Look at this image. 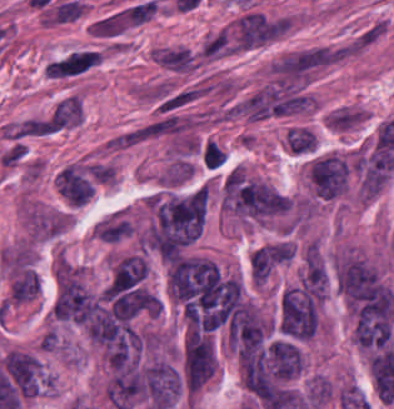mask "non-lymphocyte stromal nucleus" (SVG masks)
Instances as JSON below:
<instances>
[{"instance_id": "obj_1", "label": "non-lymphocyte stromal nucleus", "mask_w": 394, "mask_h": 409, "mask_svg": "<svg viewBox=\"0 0 394 409\" xmlns=\"http://www.w3.org/2000/svg\"><path fill=\"white\" fill-rule=\"evenodd\" d=\"M101 55L93 51H73L46 66L52 77H64L87 71Z\"/></svg>"}, {"instance_id": "obj_2", "label": "non-lymphocyte stromal nucleus", "mask_w": 394, "mask_h": 409, "mask_svg": "<svg viewBox=\"0 0 394 409\" xmlns=\"http://www.w3.org/2000/svg\"><path fill=\"white\" fill-rule=\"evenodd\" d=\"M286 143L291 151L306 153L315 148V136L306 127H293L286 136Z\"/></svg>"}]
</instances>
